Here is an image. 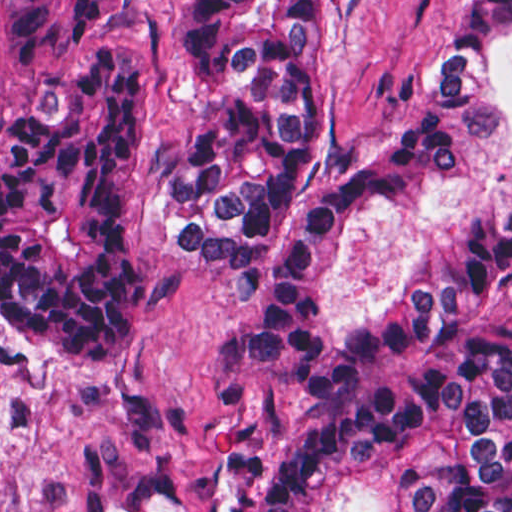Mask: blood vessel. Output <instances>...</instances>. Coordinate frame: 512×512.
Instances as JSON below:
<instances>
[{"label":"blood vessel","mask_w":512,"mask_h":512,"mask_svg":"<svg viewBox=\"0 0 512 512\" xmlns=\"http://www.w3.org/2000/svg\"><path fill=\"white\" fill-rule=\"evenodd\" d=\"M207 455L200 494L170 486L165 477L141 480L130 500L103 512H257L261 444L253 437L223 432Z\"/></svg>","instance_id":"obj_1"}]
</instances>
